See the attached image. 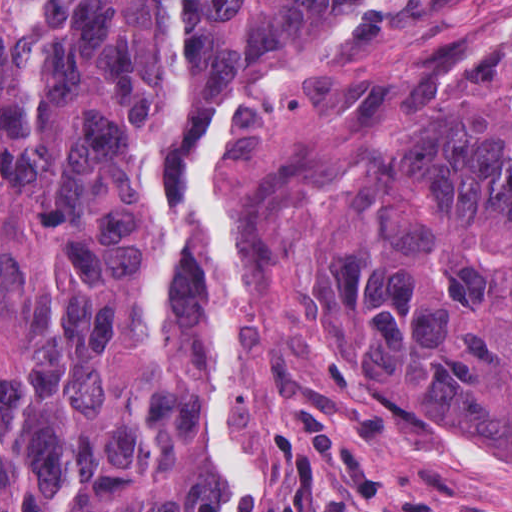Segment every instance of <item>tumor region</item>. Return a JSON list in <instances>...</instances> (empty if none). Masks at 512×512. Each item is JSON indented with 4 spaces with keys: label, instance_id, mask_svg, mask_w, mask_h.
Listing matches in <instances>:
<instances>
[{
    "label": "tumor region",
    "instance_id": "obj_1",
    "mask_svg": "<svg viewBox=\"0 0 512 512\" xmlns=\"http://www.w3.org/2000/svg\"><path fill=\"white\" fill-rule=\"evenodd\" d=\"M346 1L0 0V512L224 511L191 136ZM306 345L329 397L512 461V65L369 105Z\"/></svg>",
    "mask_w": 512,
    "mask_h": 512
}]
</instances>
